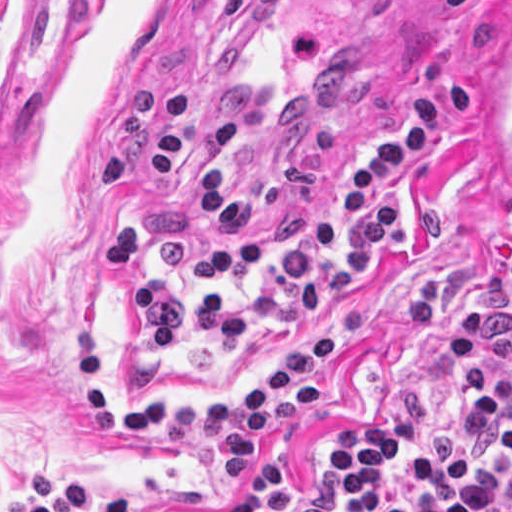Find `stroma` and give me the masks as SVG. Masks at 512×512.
<instances>
[{
    "label": "stroma",
    "instance_id": "1",
    "mask_svg": "<svg viewBox=\"0 0 512 512\" xmlns=\"http://www.w3.org/2000/svg\"><path fill=\"white\" fill-rule=\"evenodd\" d=\"M512 0H0V512L33 504L26 476L83 481L138 512H252L255 485L328 471L337 435L403 393L456 411L453 313L512 219L468 121L396 181L404 243L334 306H374L320 378L326 398L252 445L245 477L179 463L155 433L84 424L77 335L94 338L111 399L223 402L270 374L321 319L209 353L139 343L136 304L103 259V232L141 224L194 292L187 262L227 242L200 214L217 122L239 126L242 189L272 179L323 214L348 174L441 80L480 92Z\"/></svg>",
    "mask_w": 512,
    "mask_h": 512
}]
</instances>
